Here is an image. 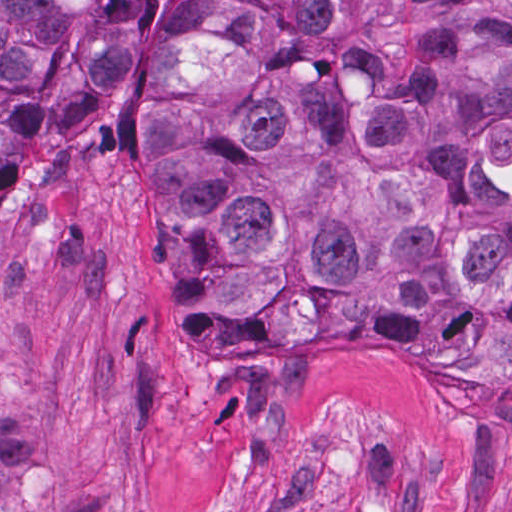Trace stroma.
Instances as JSON below:
<instances>
[{
    "instance_id": "obj_1",
    "label": "stroma",
    "mask_w": 512,
    "mask_h": 512,
    "mask_svg": "<svg viewBox=\"0 0 512 512\" xmlns=\"http://www.w3.org/2000/svg\"><path fill=\"white\" fill-rule=\"evenodd\" d=\"M175 0L113 92L0 170V395L51 512H512V404L441 356H208L179 332L126 136Z\"/></svg>"
}]
</instances>
